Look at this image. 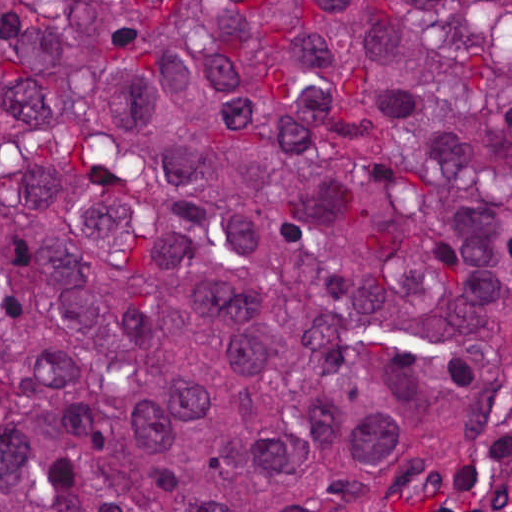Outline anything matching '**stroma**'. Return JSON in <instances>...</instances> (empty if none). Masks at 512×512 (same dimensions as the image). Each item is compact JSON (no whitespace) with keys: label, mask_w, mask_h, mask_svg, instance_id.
Returning <instances> with one entry per match:
<instances>
[{"label":"stroma","mask_w":512,"mask_h":512,"mask_svg":"<svg viewBox=\"0 0 512 512\" xmlns=\"http://www.w3.org/2000/svg\"><path fill=\"white\" fill-rule=\"evenodd\" d=\"M512 390V361L477 406L456 447L421 469L400 491L388 512H419L456 490L475 470L482 445ZM0 512H1V0H0Z\"/></svg>","instance_id":"35a3bbf8"}]
</instances>
